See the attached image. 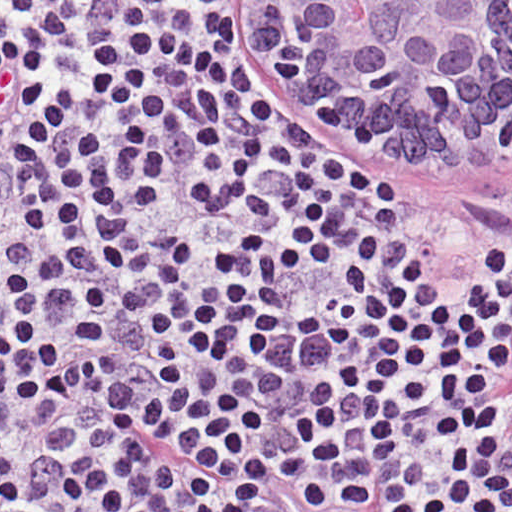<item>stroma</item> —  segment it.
Here are the masks:
<instances>
[{
    "label": "stroma",
    "mask_w": 512,
    "mask_h": 512,
    "mask_svg": "<svg viewBox=\"0 0 512 512\" xmlns=\"http://www.w3.org/2000/svg\"><path fill=\"white\" fill-rule=\"evenodd\" d=\"M234 1L229 30L232 69L246 93L270 115L318 147L336 171L375 198L387 217L421 227H477L512 243V154L471 178L403 175L406 160L308 113L293 94L286 69V22L271 1H512V0H0ZM283 494L266 488L273 512Z\"/></svg>",
    "instance_id": "1"
}]
</instances>
